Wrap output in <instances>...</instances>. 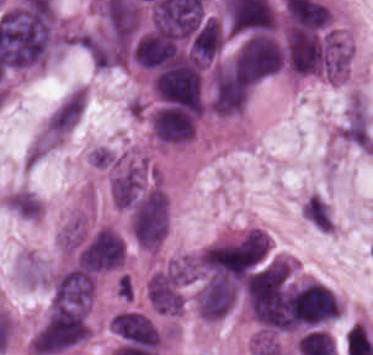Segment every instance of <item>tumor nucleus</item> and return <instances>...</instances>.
I'll list each match as a JSON object with an SVG mask.
<instances>
[{
  "label": "tumor nucleus",
  "mask_w": 373,
  "mask_h": 355,
  "mask_svg": "<svg viewBox=\"0 0 373 355\" xmlns=\"http://www.w3.org/2000/svg\"><path fill=\"white\" fill-rule=\"evenodd\" d=\"M106 177L110 202L118 210L127 211L165 191L152 155L138 149L119 154Z\"/></svg>",
  "instance_id": "2f306a5c"
},
{
  "label": "tumor nucleus",
  "mask_w": 373,
  "mask_h": 355,
  "mask_svg": "<svg viewBox=\"0 0 373 355\" xmlns=\"http://www.w3.org/2000/svg\"><path fill=\"white\" fill-rule=\"evenodd\" d=\"M90 337L87 305H52L33 332L28 351L34 355H55L81 344Z\"/></svg>",
  "instance_id": "8643909e"
},
{
  "label": "tumor nucleus",
  "mask_w": 373,
  "mask_h": 355,
  "mask_svg": "<svg viewBox=\"0 0 373 355\" xmlns=\"http://www.w3.org/2000/svg\"><path fill=\"white\" fill-rule=\"evenodd\" d=\"M335 136L347 145L373 153V131L369 123L345 116L338 125Z\"/></svg>",
  "instance_id": "2cbd58db"
},
{
  "label": "tumor nucleus",
  "mask_w": 373,
  "mask_h": 355,
  "mask_svg": "<svg viewBox=\"0 0 373 355\" xmlns=\"http://www.w3.org/2000/svg\"><path fill=\"white\" fill-rule=\"evenodd\" d=\"M87 163L97 170H109L119 164V155L111 148L94 146L87 155Z\"/></svg>",
  "instance_id": "3d1891a8"
},
{
  "label": "tumor nucleus",
  "mask_w": 373,
  "mask_h": 355,
  "mask_svg": "<svg viewBox=\"0 0 373 355\" xmlns=\"http://www.w3.org/2000/svg\"><path fill=\"white\" fill-rule=\"evenodd\" d=\"M169 223L166 192L159 183H146L127 209V233L141 250L155 252L165 239Z\"/></svg>",
  "instance_id": "5ab6c2c4"
}]
</instances>
